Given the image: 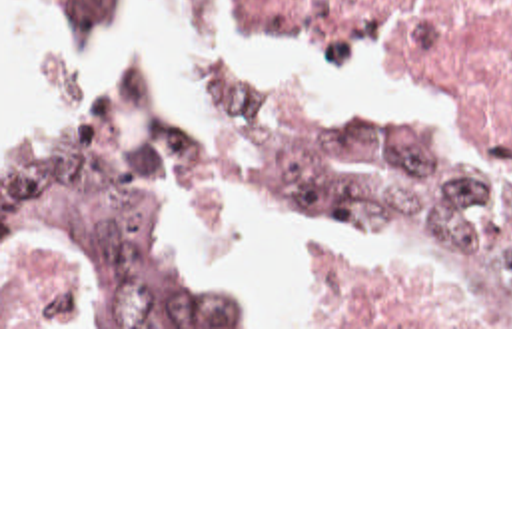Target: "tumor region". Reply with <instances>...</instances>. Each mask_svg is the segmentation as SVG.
Segmentation results:
<instances>
[{"mask_svg":"<svg viewBox=\"0 0 512 512\" xmlns=\"http://www.w3.org/2000/svg\"><path fill=\"white\" fill-rule=\"evenodd\" d=\"M70 26H120L134 0H36ZM222 141L184 133L150 79L104 87L2 157V253L60 245L116 325H252V289L184 245L182 223L270 217L383 259L445 271L483 325H512V189L393 125L308 117L272 91H226Z\"/></svg>","mask_w":512,"mask_h":512,"instance_id":"obj_1","label":"tumor region"}]
</instances>
